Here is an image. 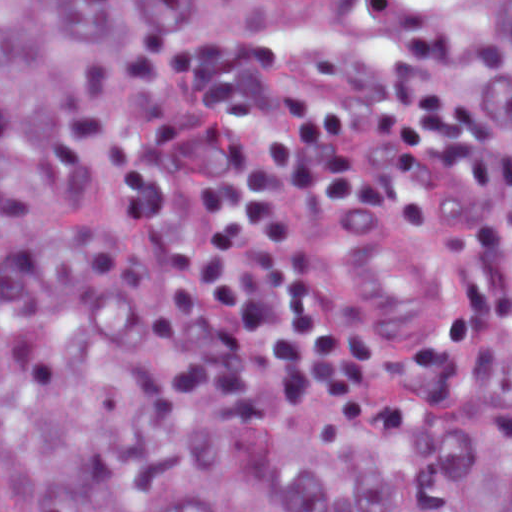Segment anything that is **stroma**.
<instances>
[{
  "label": "stroma",
  "instance_id": "1",
  "mask_svg": "<svg viewBox=\"0 0 512 512\" xmlns=\"http://www.w3.org/2000/svg\"><path fill=\"white\" fill-rule=\"evenodd\" d=\"M111 252L201 377L312 447L469 380L505 272L453 105L361 54L253 58L138 94L116 127Z\"/></svg>",
  "mask_w": 512,
  "mask_h": 512
}]
</instances>
